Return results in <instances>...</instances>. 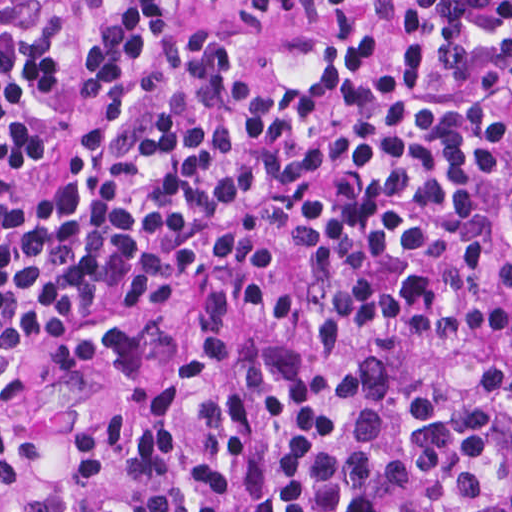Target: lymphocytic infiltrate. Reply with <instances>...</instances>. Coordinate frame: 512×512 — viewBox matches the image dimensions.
<instances>
[{
  "label": "lymphocytic infiltrate",
  "mask_w": 512,
  "mask_h": 512,
  "mask_svg": "<svg viewBox=\"0 0 512 512\" xmlns=\"http://www.w3.org/2000/svg\"><path fill=\"white\" fill-rule=\"evenodd\" d=\"M189 299L512 333V0H0V343Z\"/></svg>",
  "instance_id": "obj_1"
}]
</instances>
